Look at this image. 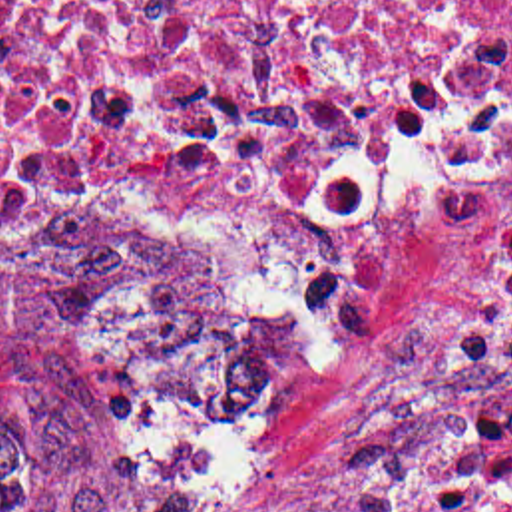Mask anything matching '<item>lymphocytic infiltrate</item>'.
<instances>
[{
  "instance_id": "1",
  "label": "lymphocytic infiltrate",
  "mask_w": 512,
  "mask_h": 512,
  "mask_svg": "<svg viewBox=\"0 0 512 512\" xmlns=\"http://www.w3.org/2000/svg\"><path fill=\"white\" fill-rule=\"evenodd\" d=\"M459 354L503 388L424 474L412 512H512V213L461 322Z\"/></svg>"
}]
</instances>
